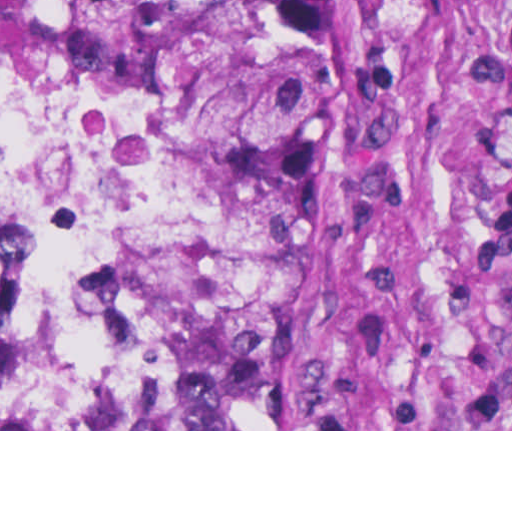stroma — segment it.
<instances>
[{
  "instance_id": "stroma-1",
  "label": "stroma",
  "mask_w": 512,
  "mask_h": 512,
  "mask_svg": "<svg viewBox=\"0 0 512 512\" xmlns=\"http://www.w3.org/2000/svg\"><path fill=\"white\" fill-rule=\"evenodd\" d=\"M512 431V0H386L287 429Z\"/></svg>"
}]
</instances>
